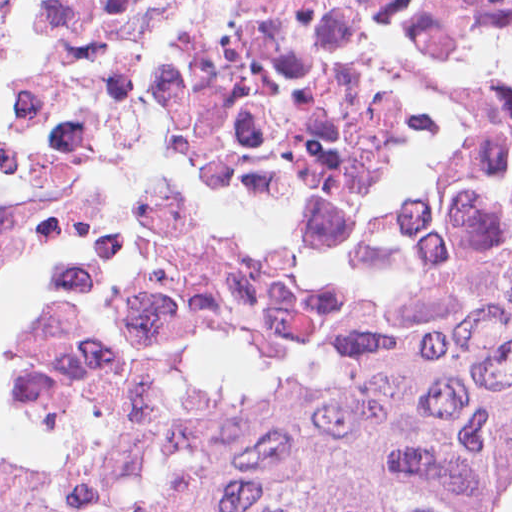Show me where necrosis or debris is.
Masks as SVG:
<instances>
[{
	"instance_id": "obj_1",
	"label": "necrosis or debris",
	"mask_w": 512,
	"mask_h": 512,
	"mask_svg": "<svg viewBox=\"0 0 512 512\" xmlns=\"http://www.w3.org/2000/svg\"><path fill=\"white\" fill-rule=\"evenodd\" d=\"M511 282L512 0H0V421L137 463Z\"/></svg>"
}]
</instances>
